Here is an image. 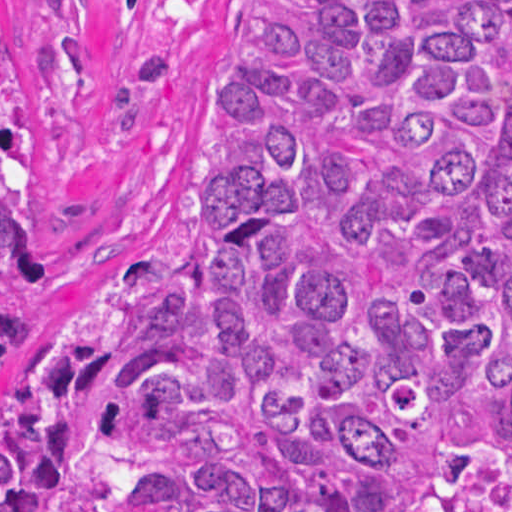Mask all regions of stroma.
Listing matches in <instances>:
<instances>
[{"label": "stroma", "instance_id": "stroma-1", "mask_svg": "<svg viewBox=\"0 0 512 512\" xmlns=\"http://www.w3.org/2000/svg\"><path fill=\"white\" fill-rule=\"evenodd\" d=\"M20 21L24 231L37 303L2 381L63 368L83 283L160 202L214 122L266 0H12Z\"/></svg>", "mask_w": 512, "mask_h": 512}]
</instances>
